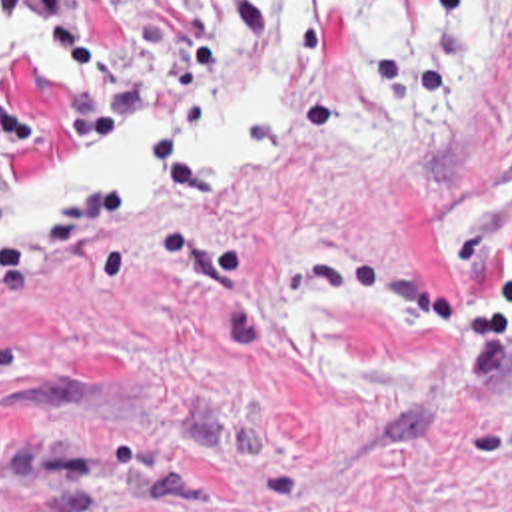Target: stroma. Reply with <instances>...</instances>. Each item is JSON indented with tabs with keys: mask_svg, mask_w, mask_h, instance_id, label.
<instances>
[{
	"mask_svg": "<svg viewBox=\"0 0 512 512\" xmlns=\"http://www.w3.org/2000/svg\"><path fill=\"white\" fill-rule=\"evenodd\" d=\"M268 1L0 0V202L209 86ZM0 512H512V0L408 136L0 254Z\"/></svg>",
	"mask_w": 512,
	"mask_h": 512,
	"instance_id": "obj_1",
	"label": "stroma"
}]
</instances>
